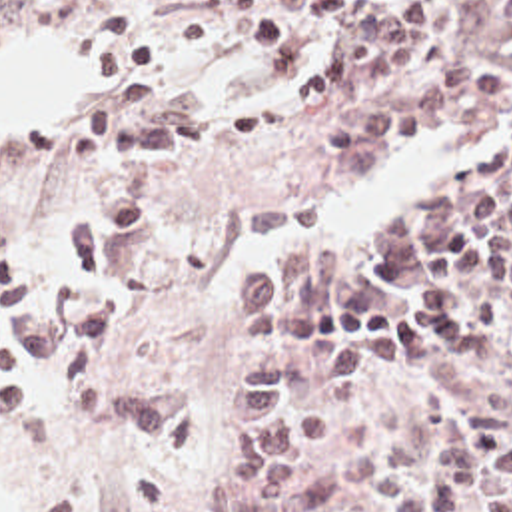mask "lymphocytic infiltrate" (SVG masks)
<instances>
[{"instance_id": "f902f5d3", "label": "lymphocytic infiltrate", "mask_w": 512, "mask_h": 512, "mask_svg": "<svg viewBox=\"0 0 512 512\" xmlns=\"http://www.w3.org/2000/svg\"><path fill=\"white\" fill-rule=\"evenodd\" d=\"M503 15L512 27V1ZM68 47L94 61L92 85L136 75L152 59L150 37L134 21L130 0H78L68 21ZM0 409L12 421L48 428L42 403L6 373H0Z\"/></svg>"}]
</instances>
